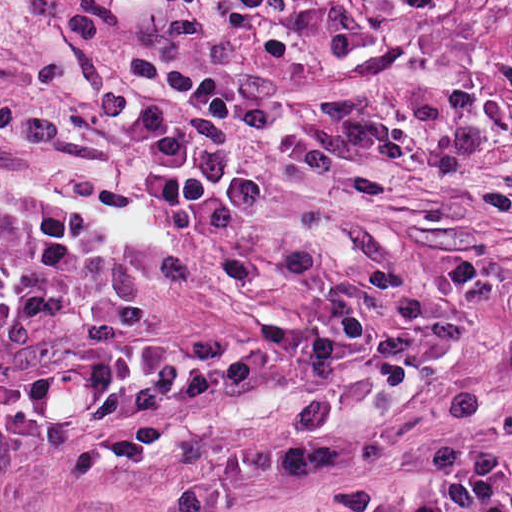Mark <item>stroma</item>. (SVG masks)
<instances>
[{
	"mask_svg": "<svg viewBox=\"0 0 512 512\" xmlns=\"http://www.w3.org/2000/svg\"><path fill=\"white\" fill-rule=\"evenodd\" d=\"M194 100L233 115L280 204L139 326L207 350L182 382L0 453V512H512V0H0V190H121L202 219ZM380 315L278 314L293 253ZM359 255L383 287L366 274Z\"/></svg>",
	"mask_w": 512,
	"mask_h": 512,
	"instance_id": "1",
	"label": "stroma"
}]
</instances>
